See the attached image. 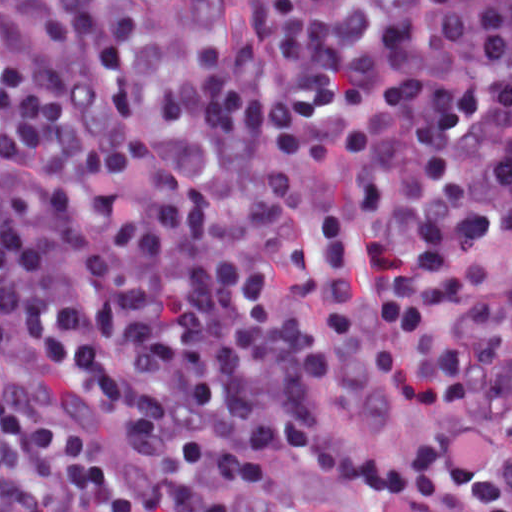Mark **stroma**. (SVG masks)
<instances>
[{"instance_id":"35a3bbf8","label":"stroma","mask_w":512,"mask_h":512,"mask_svg":"<svg viewBox=\"0 0 512 512\" xmlns=\"http://www.w3.org/2000/svg\"><path fill=\"white\" fill-rule=\"evenodd\" d=\"M369 309L355 332L327 347L330 381L323 395L325 423L338 442L375 445L410 454L425 438L431 418L418 404L393 393L374 358ZM0 512H1V0H0ZM244 512H418L385 502L353 485L304 471L289 455L272 487Z\"/></svg>"}]
</instances>
